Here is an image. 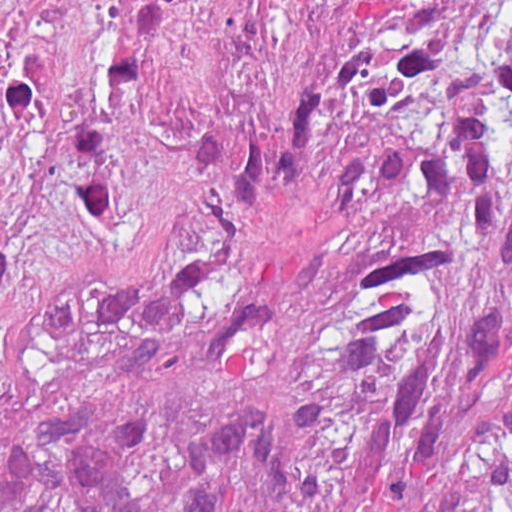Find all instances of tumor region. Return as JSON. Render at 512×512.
Returning a JSON list of instances; mask_svg holds the SVG:
<instances>
[{
  "instance_id": "e687c5a6",
  "label": "tumor region",
  "mask_w": 512,
  "mask_h": 512,
  "mask_svg": "<svg viewBox=\"0 0 512 512\" xmlns=\"http://www.w3.org/2000/svg\"><path fill=\"white\" fill-rule=\"evenodd\" d=\"M0 512H512V19L266 129L0 122Z\"/></svg>"
}]
</instances>
